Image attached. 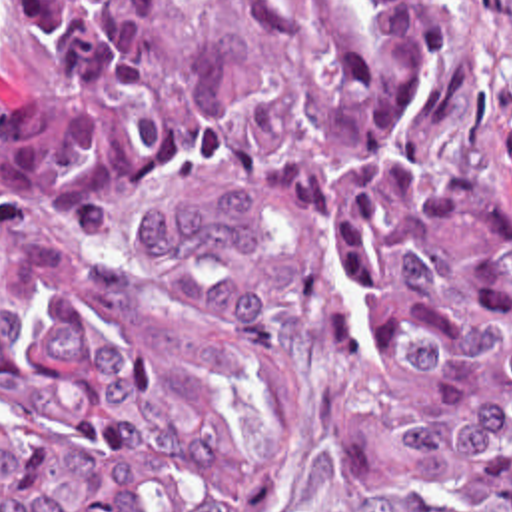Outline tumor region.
Wrapping results in <instances>:
<instances>
[{
    "instance_id": "e687c5a6",
    "label": "tumor region",
    "mask_w": 512,
    "mask_h": 512,
    "mask_svg": "<svg viewBox=\"0 0 512 512\" xmlns=\"http://www.w3.org/2000/svg\"><path fill=\"white\" fill-rule=\"evenodd\" d=\"M0 512H243L291 341L383 512H512V200L433 170L453 0H18Z\"/></svg>"
}]
</instances>
